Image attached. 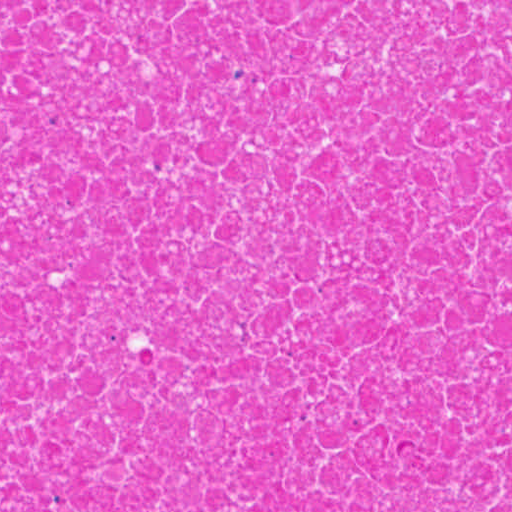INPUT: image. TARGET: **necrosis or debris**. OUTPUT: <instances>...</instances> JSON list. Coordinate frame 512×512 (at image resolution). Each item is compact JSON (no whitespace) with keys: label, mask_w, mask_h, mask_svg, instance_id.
I'll return each mask as SVG.
<instances>
[{"label":"necrosis or debris","mask_w":512,"mask_h":512,"mask_svg":"<svg viewBox=\"0 0 512 512\" xmlns=\"http://www.w3.org/2000/svg\"><path fill=\"white\" fill-rule=\"evenodd\" d=\"M0 512H512V1H0Z\"/></svg>","instance_id":"necrosis-or-debris-1"}]
</instances>
